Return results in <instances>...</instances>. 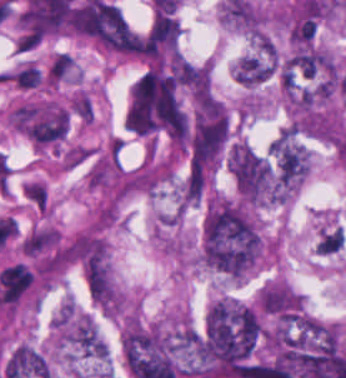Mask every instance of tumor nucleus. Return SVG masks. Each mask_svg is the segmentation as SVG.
I'll use <instances>...</instances> for the list:
<instances>
[{
	"mask_svg": "<svg viewBox=\"0 0 346 378\" xmlns=\"http://www.w3.org/2000/svg\"><path fill=\"white\" fill-rule=\"evenodd\" d=\"M253 301L274 326H295L308 312L302 295L287 279L263 281Z\"/></svg>",
	"mask_w": 346,
	"mask_h": 378,
	"instance_id": "tumor-nucleus-4",
	"label": "tumor nucleus"
},
{
	"mask_svg": "<svg viewBox=\"0 0 346 378\" xmlns=\"http://www.w3.org/2000/svg\"><path fill=\"white\" fill-rule=\"evenodd\" d=\"M69 117L63 104L50 99L24 101L13 108L14 127L44 148L61 141Z\"/></svg>",
	"mask_w": 346,
	"mask_h": 378,
	"instance_id": "tumor-nucleus-3",
	"label": "tumor nucleus"
},
{
	"mask_svg": "<svg viewBox=\"0 0 346 378\" xmlns=\"http://www.w3.org/2000/svg\"><path fill=\"white\" fill-rule=\"evenodd\" d=\"M269 154L283 188L296 191L310 168V154L297 137L282 130L270 143Z\"/></svg>",
	"mask_w": 346,
	"mask_h": 378,
	"instance_id": "tumor-nucleus-5",
	"label": "tumor nucleus"
},
{
	"mask_svg": "<svg viewBox=\"0 0 346 378\" xmlns=\"http://www.w3.org/2000/svg\"><path fill=\"white\" fill-rule=\"evenodd\" d=\"M80 69L69 53L56 52L47 64L42 81L49 88H60L78 83Z\"/></svg>",
	"mask_w": 346,
	"mask_h": 378,
	"instance_id": "tumor-nucleus-6",
	"label": "tumor nucleus"
},
{
	"mask_svg": "<svg viewBox=\"0 0 346 378\" xmlns=\"http://www.w3.org/2000/svg\"><path fill=\"white\" fill-rule=\"evenodd\" d=\"M264 323L247 300L222 295L207 308L197 354L199 362H249L257 353Z\"/></svg>",
	"mask_w": 346,
	"mask_h": 378,
	"instance_id": "tumor-nucleus-1",
	"label": "tumor nucleus"
},
{
	"mask_svg": "<svg viewBox=\"0 0 346 378\" xmlns=\"http://www.w3.org/2000/svg\"><path fill=\"white\" fill-rule=\"evenodd\" d=\"M226 168L237 196L251 206L278 203L280 187L267 155L240 138L227 143Z\"/></svg>",
	"mask_w": 346,
	"mask_h": 378,
	"instance_id": "tumor-nucleus-2",
	"label": "tumor nucleus"
}]
</instances>
